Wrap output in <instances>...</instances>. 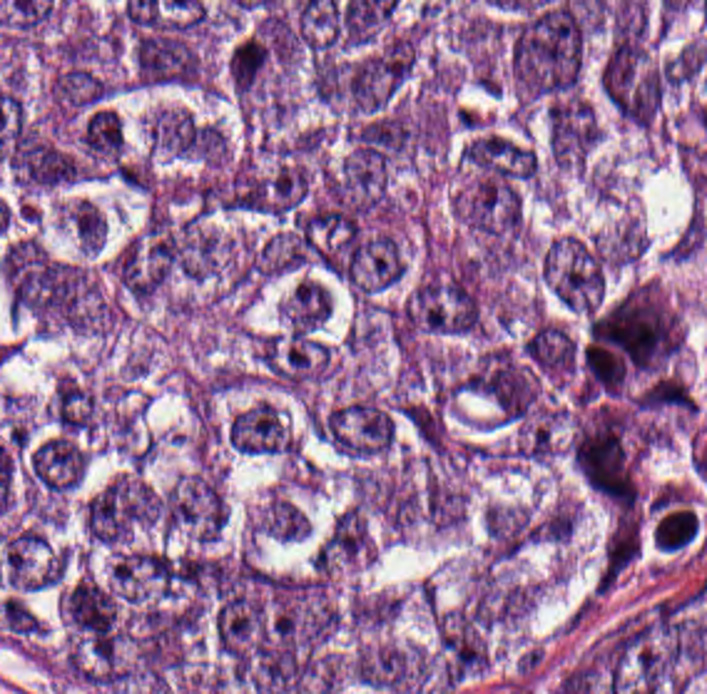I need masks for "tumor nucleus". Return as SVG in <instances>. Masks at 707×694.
I'll return each instance as SVG.
<instances>
[{
	"instance_id": "tumor-nucleus-1",
	"label": "tumor nucleus",
	"mask_w": 707,
	"mask_h": 694,
	"mask_svg": "<svg viewBox=\"0 0 707 694\" xmlns=\"http://www.w3.org/2000/svg\"><path fill=\"white\" fill-rule=\"evenodd\" d=\"M350 678L370 690L418 694L426 687V647L377 640L352 652Z\"/></svg>"
},
{
	"instance_id": "tumor-nucleus-2",
	"label": "tumor nucleus",
	"mask_w": 707,
	"mask_h": 694,
	"mask_svg": "<svg viewBox=\"0 0 707 694\" xmlns=\"http://www.w3.org/2000/svg\"><path fill=\"white\" fill-rule=\"evenodd\" d=\"M544 157L564 166L585 165L595 143V119L583 99L557 96L542 114Z\"/></svg>"
},
{
	"instance_id": "tumor-nucleus-3",
	"label": "tumor nucleus",
	"mask_w": 707,
	"mask_h": 694,
	"mask_svg": "<svg viewBox=\"0 0 707 694\" xmlns=\"http://www.w3.org/2000/svg\"><path fill=\"white\" fill-rule=\"evenodd\" d=\"M104 401L95 383L75 373H61L46 402V431L92 444Z\"/></svg>"
},
{
	"instance_id": "tumor-nucleus-4",
	"label": "tumor nucleus",
	"mask_w": 707,
	"mask_h": 694,
	"mask_svg": "<svg viewBox=\"0 0 707 694\" xmlns=\"http://www.w3.org/2000/svg\"><path fill=\"white\" fill-rule=\"evenodd\" d=\"M223 435L230 451L245 456H291L294 451L285 415L271 400L260 398L233 413Z\"/></svg>"
},
{
	"instance_id": "tumor-nucleus-5",
	"label": "tumor nucleus",
	"mask_w": 707,
	"mask_h": 694,
	"mask_svg": "<svg viewBox=\"0 0 707 694\" xmlns=\"http://www.w3.org/2000/svg\"><path fill=\"white\" fill-rule=\"evenodd\" d=\"M371 537L358 505H345L310 540L308 568L331 572L361 558Z\"/></svg>"
},
{
	"instance_id": "tumor-nucleus-6",
	"label": "tumor nucleus",
	"mask_w": 707,
	"mask_h": 694,
	"mask_svg": "<svg viewBox=\"0 0 707 694\" xmlns=\"http://www.w3.org/2000/svg\"><path fill=\"white\" fill-rule=\"evenodd\" d=\"M168 502L167 490L158 487L90 541L89 546L124 550L157 528Z\"/></svg>"
},
{
	"instance_id": "tumor-nucleus-7",
	"label": "tumor nucleus",
	"mask_w": 707,
	"mask_h": 694,
	"mask_svg": "<svg viewBox=\"0 0 707 694\" xmlns=\"http://www.w3.org/2000/svg\"><path fill=\"white\" fill-rule=\"evenodd\" d=\"M309 521L296 501L272 491L262 502L250 528L273 541H294L307 531Z\"/></svg>"
},
{
	"instance_id": "tumor-nucleus-8",
	"label": "tumor nucleus",
	"mask_w": 707,
	"mask_h": 694,
	"mask_svg": "<svg viewBox=\"0 0 707 694\" xmlns=\"http://www.w3.org/2000/svg\"><path fill=\"white\" fill-rule=\"evenodd\" d=\"M104 221L99 208L79 196L69 204L64 224L76 244L97 252L102 244Z\"/></svg>"
}]
</instances>
